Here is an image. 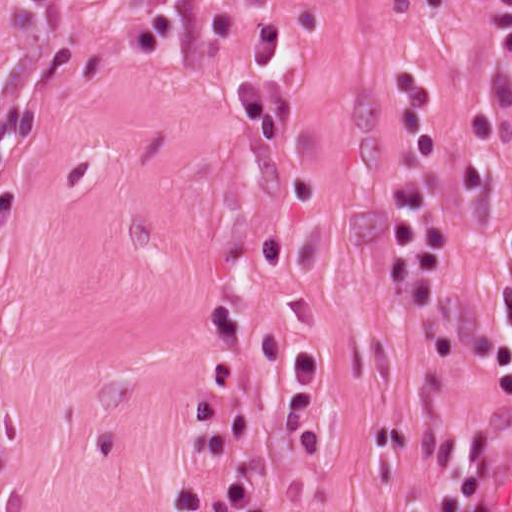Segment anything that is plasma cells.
<instances>
[{
  "instance_id": "9512152a",
  "label": "plasma cells",
  "mask_w": 512,
  "mask_h": 512,
  "mask_svg": "<svg viewBox=\"0 0 512 512\" xmlns=\"http://www.w3.org/2000/svg\"><path fill=\"white\" fill-rule=\"evenodd\" d=\"M280 58L279 25L275 18L265 20L252 57L233 82L248 138L260 150L277 147L297 113V99L274 80ZM447 111L442 81L432 69H400L380 86V113L393 153L384 185L381 286L417 323L430 361L440 367L487 365L499 395L512 400V233L498 277L503 321L459 330L439 304L453 233L451 222L435 212L439 134ZM236 378L229 357L201 385L206 461L232 460L251 446L255 414L228 403ZM246 472L192 490L178 512H239L235 481ZM404 512H483L473 452H441L404 497Z\"/></svg>"
}]
</instances>
